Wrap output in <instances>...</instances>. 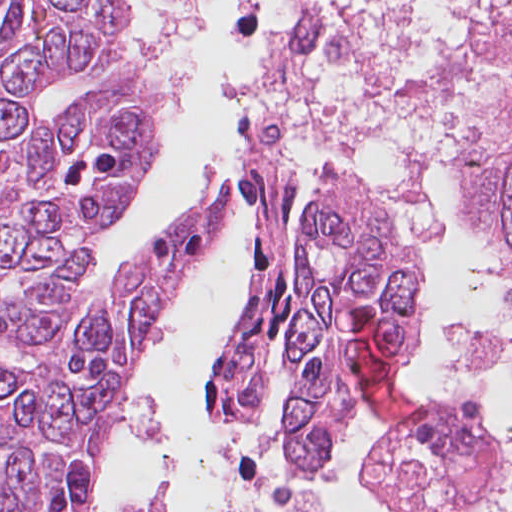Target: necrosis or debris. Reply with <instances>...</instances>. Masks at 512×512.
I'll list each match as a JSON object with an SVG mask.
<instances>
[{"label":"necrosis or debris","instance_id":"obj_1","mask_svg":"<svg viewBox=\"0 0 512 512\" xmlns=\"http://www.w3.org/2000/svg\"><path fill=\"white\" fill-rule=\"evenodd\" d=\"M460 364L486 384L428 407L387 444L410 512H512V336L469 338Z\"/></svg>","mask_w":512,"mask_h":512}]
</instances>
